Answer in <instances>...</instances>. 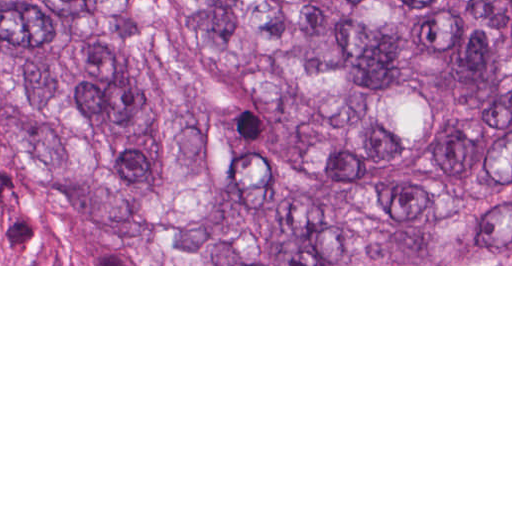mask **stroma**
<instances>
[{"label": "stroma", "mask_w": 512, "mask_h": 512, "mask_svg": "<svg viewBox=\"0 0 512 512\" xmlns=\"http://www.w3.org/2000/svg\"><path fill=\"white\" fill-rule=\"evenodd\" d=\"M472 220L346 243L337 264H180L83 198L59 169L0 137V266H512Z\"/></svg>", "instance_id": "35a3bbf8"}]
</instances>
